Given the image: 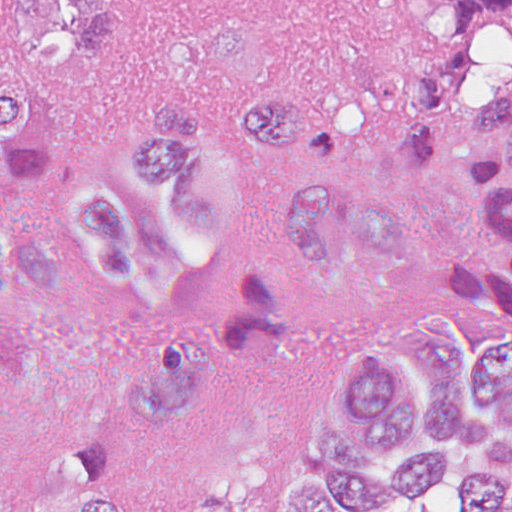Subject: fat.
<instances>
[{
	"label": "fat",
	"mask_w": 512,
	"mask_h": 512,
	"mask_svg": "<svg viewBox=\"0 0 512 512\" xmlns=\"http://www.w3.org/2000/svg\"><path fill=\"white\" fill-rule=\"evenodd\" d=\"M512 71V19H500L469 43V66L457 103L478 117L496 104Z\"/></svg>",
	"instance_id": "53f6f03d"
}]
</instances>
